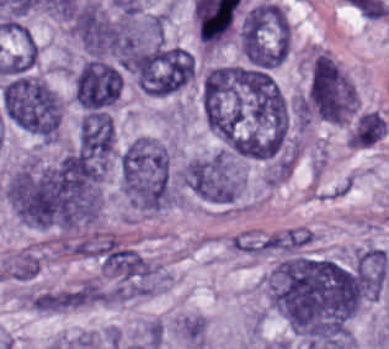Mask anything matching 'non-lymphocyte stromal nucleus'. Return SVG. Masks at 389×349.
<instances>
[{
	"mask_svg": "<svg viewBox=\"0 0 389 349\" xmlns=\"http://www.w3.org/2000/svg\"><path fill=\"white\" fill-rule=\"evenodd\" d=\"M320 234L311 226L293 225L236 233L235 254L251 259L287 256L311 250Z\"/></svg>",
	"mask_w": 389,
	"mask_h": 349,
	"instance_id": "non-lymphocyte-stromal-nucleus-1",
	"label": "non-lymphocyte stromal nucleus"
},
{
	"mask_svg": "<svg viewBox=\"0 0 389 349\" xmlns=\"http://www.w3.org/2000/svg\"><path fill=\"white\" fill-rule=\"evenodd\" d=\"M178 332L192 349H203L208 332V322L201 315L189 313L178 320Z\"/></svg>",
	"mask_w": 389,
	"mask_h": 349,
	"instance_id": "non-lymphocyte-stromal-nucleus-2",
	"label": "non-lymphocyte stromal nucleus"
}]
</instances>
